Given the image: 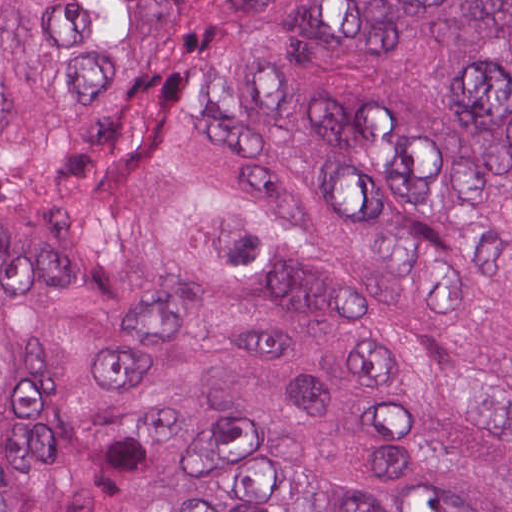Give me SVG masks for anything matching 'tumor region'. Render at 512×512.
Wrapping results in <instances>:
<instances>
[{"instance_id":"obj_1","label":"tumor region","mask_w":512,"mask_h":512,"mask_svg":"<svg viewBox=\"0 0 512 512\" xmlns=\"http://www.w3.org/2000/svg\"><path fill=\"white\" fill-rule=\"evenodd\" d=\"M0 512H512V0H0Z\"/></svg>"}]
</instances>
